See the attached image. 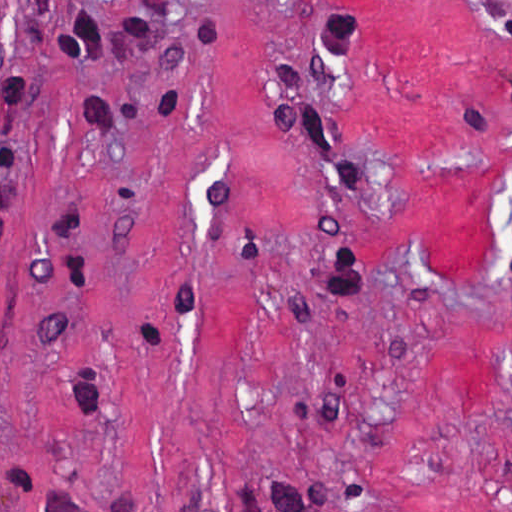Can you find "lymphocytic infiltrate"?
<instances>
[{
	"instance_id": "obj_1",
	"label": "lymphocytic infiltrate",
	"mask_w": 512,
	"mask_h": 512,
	"mask_svg": "<svg viewBox=\"0 0 512 512\" xmlns=\"http://www.w3.org/2000/svg\"><path fill=\"white\" fill-rule=\"evenodd\" d=\"M512 183V170L507 174ZM512 261V256H509ZM293 512H344L339 504L331 497L318 494H308Z\"/></svg>"
}]
</instances>
